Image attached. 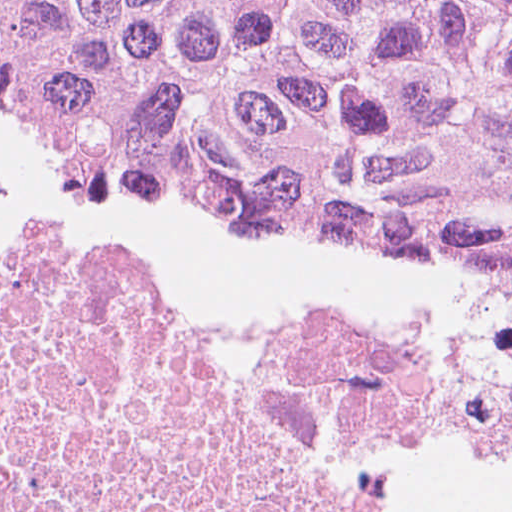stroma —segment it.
Here are the masks:
<instances>
[{"label":"stroma","mask_w":512,"mask_h":512,"mask_svg":"<svg viewBox=\"0 0 512 512\" xmlns=\"http://www.w3.org/2000/svg\"><path fill=\"white\" fill-rule=\"evenodd\" d=\"M0 182L60 206L142 289L224 324H342L445 290L484 259L230 197L147 153L53 125L0 95Z\"/></svg>","instance_id":"obj_1"}]
</instances>
